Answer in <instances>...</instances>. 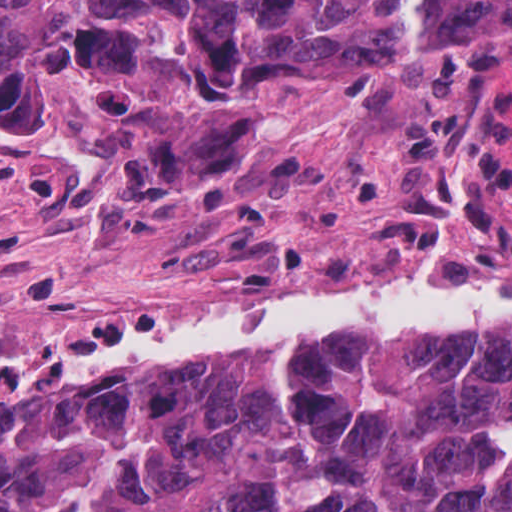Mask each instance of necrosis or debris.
Returning <instances> with one entry per match:
<instances>
[{
  "mask_svg": "<svg viewBox=\"0 0 512 512\" xmlns=\"http://www.w3.org/2000/svg\"><path fill=\"white\" fill-rule=\"evenodd\" d=\"M425 275H512V150L469 90L261 196L251 224L148 304L94 294L0 310V357L65 349L229 298L288 308Z\"/></svg>",
  "mask_w": 512,
  "mask_h": 512,
  "instance_id": "obj_1",
  "label": "necrosis or debris"
}]
</instances>
